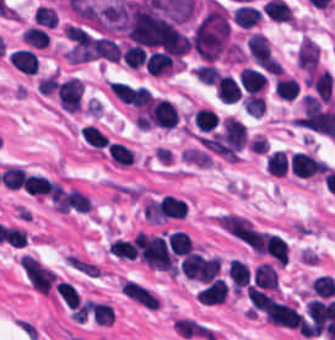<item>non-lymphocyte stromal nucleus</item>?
<instances>
[{
	"mask_svg": "<svg viewBox=\"0 0 335 340\" xmlns=\"http://www.w3.org/2000/svg\"><path fill=\"white\" fill-rule=\"evenodd\" d=\"M120 288L128 299L148 309L155 310L159 304L152 291L140 283L130 279H123Z\"/></svg>",
	"mask_w": 335,
	"mask_h": 340,
	"instance_id": "3746e769",
	"label": "non-lymphocyte stromal nucleus"
},
{
	"mask_svg": "<svg viewBox=\"0 0 335 340\" xmlns=\"http://www.w3.org/2000/svg\"><path fill=\"white\" fill-rule=\"evenodd\" d=\"M175 331L182 337L214 340L213 330L193 316H180L175 321Z\"/></svg>",
	"mask_w": 335,
	"mask_h": 340,
	"instance_id": "a72fc3eb",
	"label": "non-lymphocyte stromal nucleus"
},
{
	"mask_svg": "<svg viewBox=\"0 0 335 340\" xmlns=\"http://www.w3.org/2000/svg\"><path fill=\"white\" fill-rule=\"evenodd\" d=\"M23 275L32 288L40 294L57 296L59 276L36 256H23Z\"/></svg>",
	"mask_w": 335,
	"mask_h": 340,
	"instance_id": "dd21d789",
	"label": "non-lymphocyte stromal nucleus"
}]
</instances>
